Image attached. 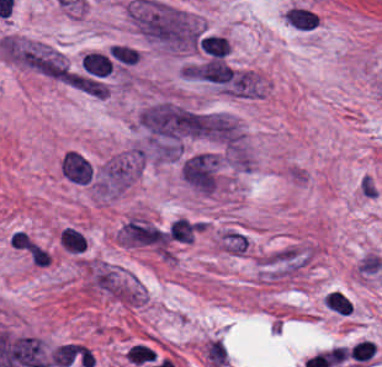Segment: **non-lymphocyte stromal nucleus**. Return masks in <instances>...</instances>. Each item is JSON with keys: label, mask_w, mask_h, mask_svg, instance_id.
<instances>
[{"label": "non-lymphocyte stromal nucleus", "mask_w": 382, "mask_h": 367, "mask_svg": "<svg viewBox=\"0 0 382 367\" xmlns=\"http://www.w3.org/2000/svg\"><path fill=\"white\" fill-rule=\"evenodd\" d=\"M314 245L291 244L256 258L259 280L279 284L303 275L318 259Z\"/></svg>", "instance_id": "3"}, {"label": "non-lymphocyte stromal nucleus", "mask_w": 382, "mask_h": 367, "mask_svg": "<svg viewBox=\"0 0 382 367\" xmlns=\"http://www.w3.org/2000/svg\"><path fill=\"white\" fill-rule=\"evenodd\" d=\"M197 220L179 217L168 228V236L172 243H191L198 233Z\"/></svg>", "instance_id": "4"}, {"label": "non-lymphocyte stromal nucleus", "mask_w": 382, "mask_h": 367, "mask_svg": "<svg viewBox=\"0 0 382 367\" xmlns=\"http://www.w3.org/2000/svg\"><path fill=\"white\" fill-rule=\"evenodd\" d=\"M129 18L145 41L170 50L198 45L199 19L161 0H129Z\"/></svg>", "instance_id": "1"}, {"label": "non-lymphocyte stromal nucleus", "mask_w": 382, "mask_h": 367, "mask_svg": "<svg viewBox=\"0 0 382 367\" xmlns=\"http://www.w3.org/2000/svg\"><path fill=\"white\" fill-rule=\"evenodd\" d=\"M1 49L8 59L49 79L67 80L71 77L64 57L40 41L3 36Z\"/></svg>", "instance_id": "2"}]
</instances>
